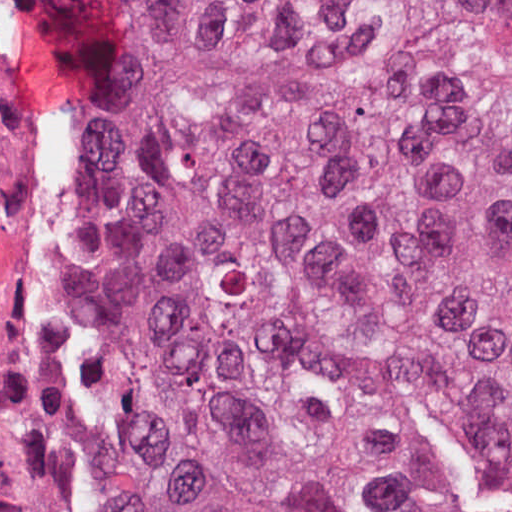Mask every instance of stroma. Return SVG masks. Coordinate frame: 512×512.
Segmentation results:
<instances>
[{
    "label": "stroma",
    "instance_id": "1",
    "mask_svg": "<svg viewBox=\"0 0 512 512\" xmlns=\"http://www.w3.org/2000/svg\"><path fill=\"white\" fill-rule=\"evenodd\" d=\"M0 512H169L159 220L31 0H0Z\"/></svg>",
    "mask_w": 512,
    "mask_h": 512
}]
</instances>
